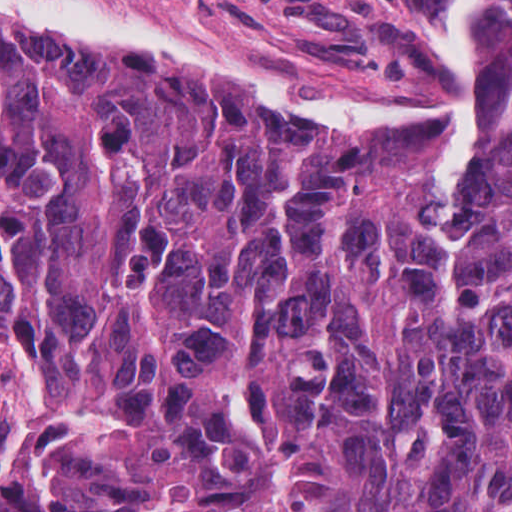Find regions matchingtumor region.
I'll use <instances>...</instances> for the list:
<instances>
[{
  "instance_id": "e687c5a6",
  "label": "tumor region",
  "mask_w": 512,
  "mask_h": 512,
  "mask_svg": "<svg viewBox=\"0 0 512 512\" xmlns=\"http://www.w3.org/2000/svg\"><path fill=\"white\" fill-rule=\"evenodd\" d=\"M434 159L0 19V512H512V0Z\"/></svg>"
}]
</instances>
